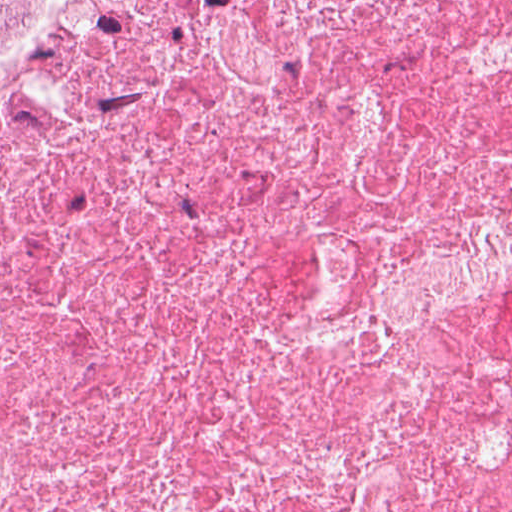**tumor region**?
Masks as SVG:
<instances>
[{
    "mask_svg": "<svg viewBox=\"0 0 512 512\" xmlns=\"http://www.w3.org/2000/svg\"><path fill=\"white\" fill-rule=\"evenodd\" d=\"M84 0H0V53L45 28Z\"/></svg>",
    "mask_w": 512,
    "mask_h": 512,
    "instance_id": "obj_1",
    "label": "tumor region"
}]
</instances>
